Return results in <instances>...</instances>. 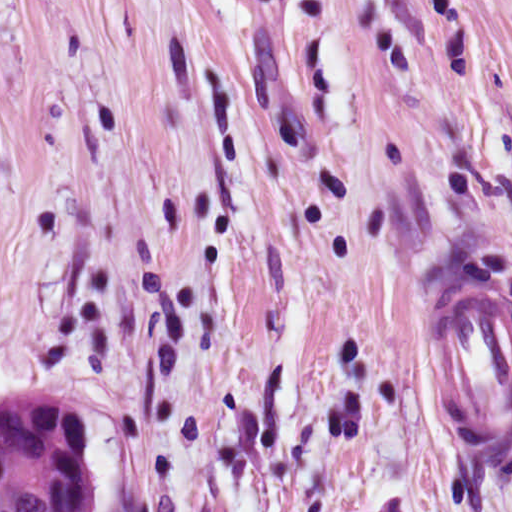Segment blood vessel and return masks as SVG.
I'll return each mask as SVG.
<instances>
[{
  "mask_svg": "<svg viewBox=\"0 0 512 512\" xmlns=\"http://www.w3.org/2000/svg\"><path fill=\"white\" fill-rule=\"evenodd\" d=\"M483 275L441 289L426 354L442 413L483 463L512 461V299Z\"/></svg>",
  "mask_w": 512,
  "mask_h": 512,
  "instance_id": "obj_1",
  "label": "blood vessel"
}]
</instances>
